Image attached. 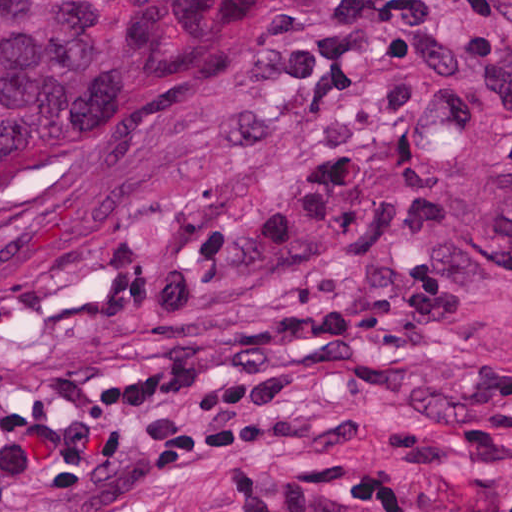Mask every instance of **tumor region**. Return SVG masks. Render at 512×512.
<instances>
[{"instance_id":"1","label":"tumor region","mask_w":512,"mask_h":512,"mask_svg":"<svg viewBox=\"0 0 512 512\" xmlns=\"http://www.w3.org/2000/svg\"><path fill=\"white\" fill-rule=\"evenodd\" d=\"M256 0H0V222L102 181L199 115Z\"/></svg>"}]
</instances>
